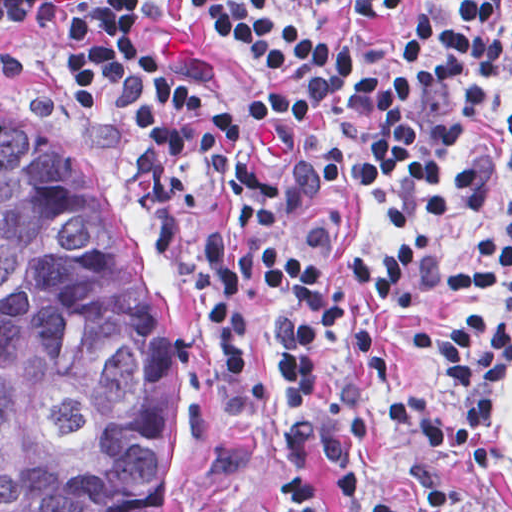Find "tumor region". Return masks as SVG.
Returning <instances> with one entry per match:
<instances>
[{
	"label": "tumor region",
	"instance_id": "1",
	"mask_svg": "<svg viewBox=\"0 0 512 512\" xmlns=\"http://www.w3.org/2000/svg\"><path fill=\"white\" fill-rule=\"evenodd\" d=\"M169 306L83 140L0 120V512H154Z\"/></svg>",
	"mask_w": 512,
	"mask_h": 512
}]
</instances>
